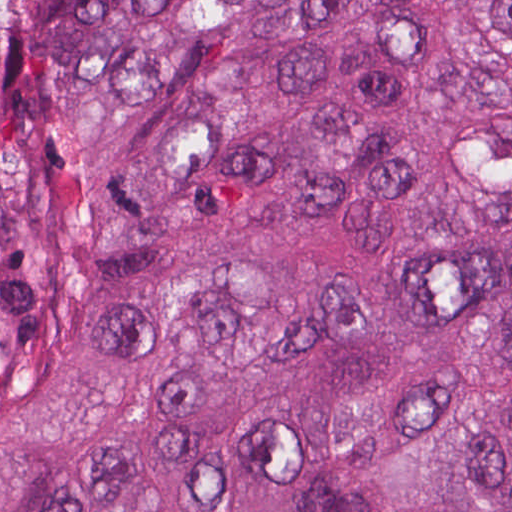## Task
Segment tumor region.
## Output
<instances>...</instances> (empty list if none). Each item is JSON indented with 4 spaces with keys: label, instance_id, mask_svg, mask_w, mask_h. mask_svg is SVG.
Here are the masks:
<instances>
[{
    "label": "tumor region",
    "instance_id": "tumor-region-1",
    "mask_svg": "<svg viewBox=\"0 0 512 512\" xmlns=\"http://www.w3.org/2000/svg\"><path fill=\"white\" fill-rule=\"evenodd\" d=\"M0 512H512V0H0Z\"/></svg>",
    "mask_w": 512,
    "mask_h": 512
}]
</instances>
